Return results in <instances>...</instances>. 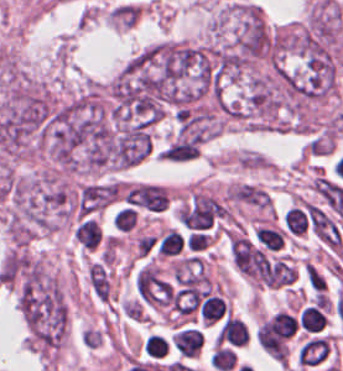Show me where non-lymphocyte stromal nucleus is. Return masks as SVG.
I'll use <instances>...</instances> for the list:
<instances>
[{
  "label": "non-lymphocyte stromal nucleus",
  "instance_id": "2",
  "mask_svg": "<svg viewBox=\"0 0 343 371\" xmlns=\"http://www.w3.org/2000/svg\"><path fill=\"white\" fill-rule=\"evenodd\" d=\"M305 274L307 284L312 292L323 294L326 291V279L312 262H305Z\"/></svg>",
  "mask_w": 343,
  "mask_h": 371
},
{
  "label": "non-lymphocyte stromal nucleus",
  "instance_id": "1",
  "mask_svg": "<svg viewBox=\"0 0 343 371\" xmlns=\"http://www.w3.org/2000/svg\"><path fill=\"white\" fill-rule=\"evenodd\" d=\"M74 201L76 216L89 218L116 201L115 183L93 182L81 186Z\"/></svg>",
  "mask_w": 343,
  "mask_h": 371
}]
</instances>
